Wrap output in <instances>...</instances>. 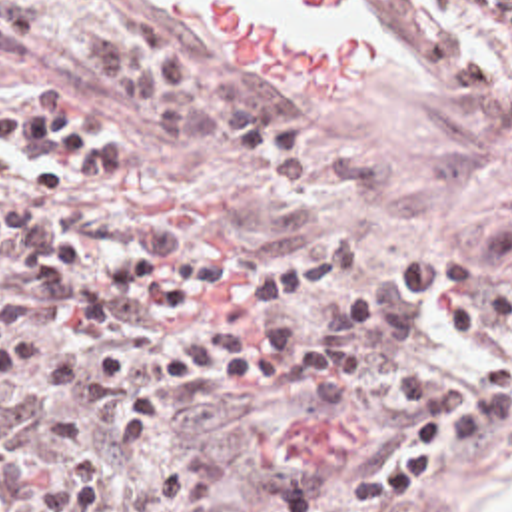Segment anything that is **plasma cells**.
I'll return each mask as SVG.
<instances>
[{"label":"plasma cells","mask_w":512,"mask_h":512,"mask_svg":"<svg viewBox=\"0 0 512 512\" xmlns=\"http://www.w3.org/2000/svg\"><path fill=\"white\" fill-rule=\"evenodd\" d=\"M506 463L512 198L464 254L305 261L179 226L109 122L0 106V512H444Z\"/></svg>","instance_id":"9512152a"}]
</instances>
